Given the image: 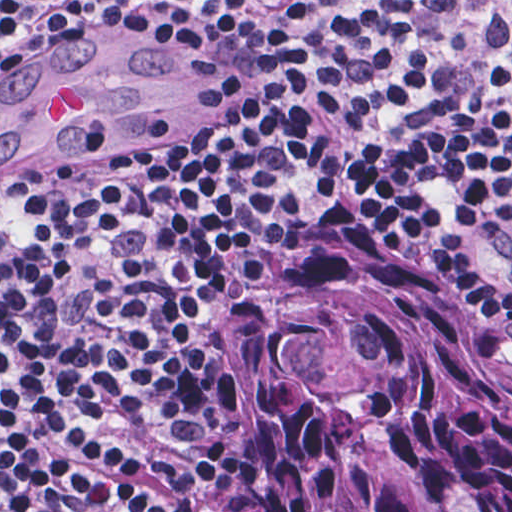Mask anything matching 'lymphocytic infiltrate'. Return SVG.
<instances>
[{
  "label": "lymphocytic infiltrate",
  "mask_w": 512,
  "mask_h": 512,
  "mask_svg": "<svg viewBox=\"0 0 512 512\" xmlns=\"http://www.w3.org/2000/svg\"><path fill=\"white\" fill-rule=\"evenodd\" d=\"M117 2L0 1V81ZM195 41L187 127L0 184V512H267L231 318L332 194L501 336L512 1H210Z\"/></svg>",
  "instance_id": "obj_1"
}]
</instances>
